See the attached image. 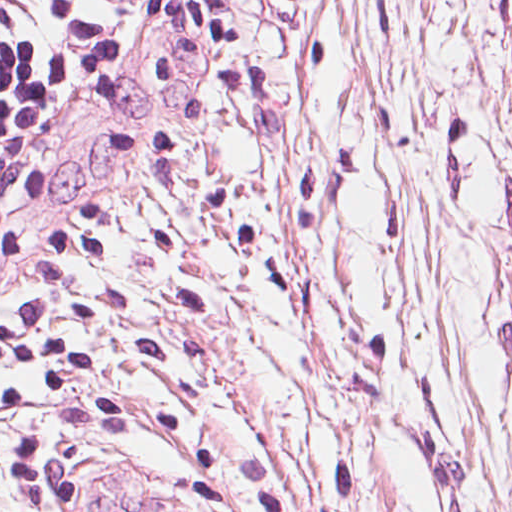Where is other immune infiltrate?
I'll use <instances>...</instances> for the list:
<instances>
[{
  "instance_id": "bc1004c8",
  "label": "other immune infiltrate",
  "mask_w": 512,
  "mask_h": 512,
  "mask_svg": "<svg viewBox=\"0 0 512 512\" xmlns=\"http://www.w3.org/2000/svg\"><path fill=\"white\" fill-rule=\"evenodd\" d=\"M85 2L89 33L46 96L39 120L124 64L140 42L152 6V0Z\"/></svg>"
}]
</instances>
